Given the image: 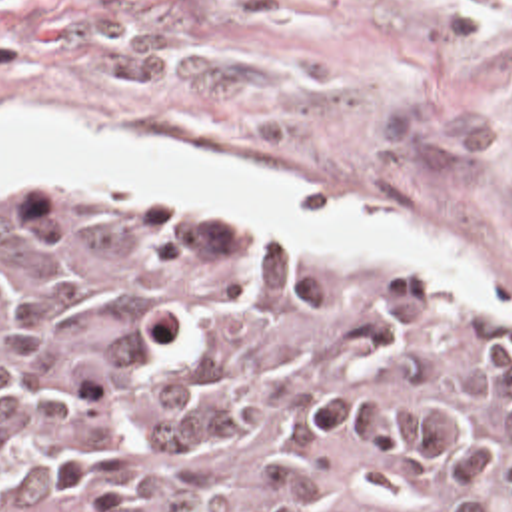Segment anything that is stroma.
Masks as SVG:
<instances>
[{
    "label": "stroma",
    "instance_id": "stroma-1",
    "mask_svg": "<svg viewBox=\"0 0 512 512\" xmlns=\"http://www.w3.org/2000/svg\"><path fill=\"white\" fill-rule=\"evenodd\" d=\"M0 115L365 197L441 227L481 277L357 259L235 205L0 189V215L223 219L512 315V0H0Z\"/></svg>",
    "mask_w": 512,
    "mask_h": 512
}]
</instances>
